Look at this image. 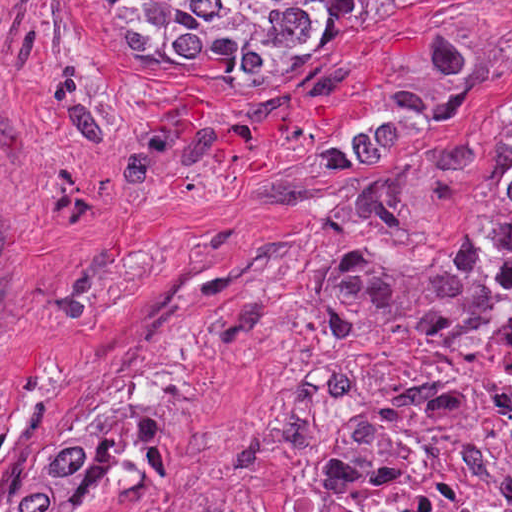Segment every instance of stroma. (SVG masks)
Segmentation results:
<instances>
[{
  "mask_svg": "<svg viewBox=\"0 0 512 512\" xmlns=\"http://www.w3.org/2000/svg\"><path fill=\"white\" fill-rule=\"evenodd\" d=\"M511 120L512 0L368 12L254 80L132 70L97 0H0V465L109 437L73 512H288L413 382L339 336L325 262L438 250Z\"/></svg>",
  "mask_w": 512,
  "mask_h": 512,
  "instance_id": "1",
  "label": "stroma"
}]
</instances>
